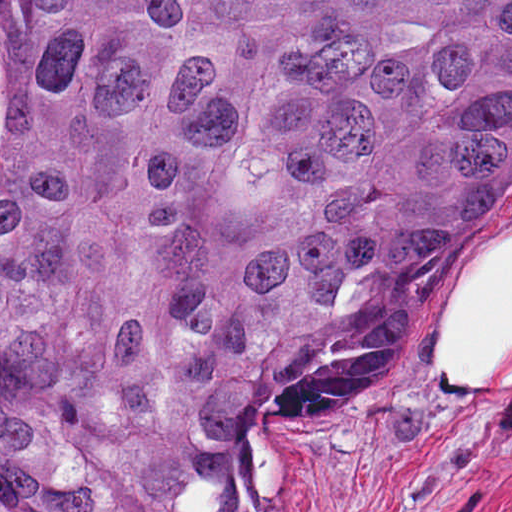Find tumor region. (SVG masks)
Returning a JSON list of instances; mask_svg holds the SVG:
<instances>
[{
    "label": "tumor region",
    "mask_w": 512,
    "mask_h": 512,
    "mask_svg": "<svg viewBox=\"0 0 512 512\" xmlns=\"http://www.w3.org/2000/svg\"><path fill=\"white\" fill-rule=\"evenodd\" d=\"M512 160V0H0V512H228Z\"/></svg>",
    "instance_id": "e687c5a6"
}]
</instances>
